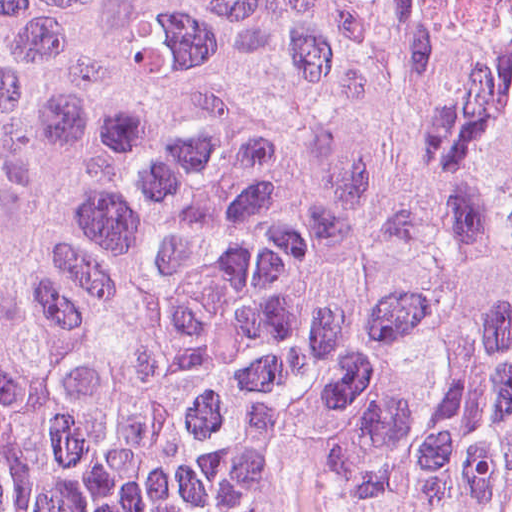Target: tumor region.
Segmentation results:
<instances>
[{"mask_svg":"<svg viewBox=\"0 0 512 512\" xmlns=\"http://www.w3.org/2000/svg\"><path fill=\"white\" fill-rule=\"evenodd\" d=\"M0 512H512V0H0Z\"/></svg>","mask_w":512,"mask_h":512,"instance_id":"tumor-region-1","label":"tumor region"}]
</instances>
